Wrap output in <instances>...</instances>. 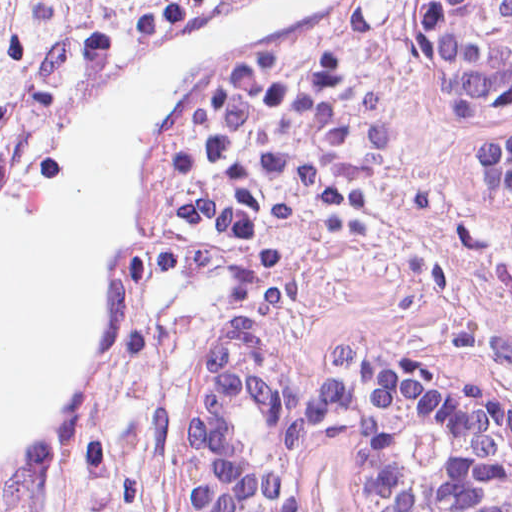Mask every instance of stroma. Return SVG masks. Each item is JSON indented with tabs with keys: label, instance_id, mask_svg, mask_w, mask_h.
Returning <instances> with one entry per match:
<instances>
[{
	"label": "stroma",
	"instance_id": "stroma-1",
	"mask_svg": "<svg viewBox=\"0 0 512 512\" xmlns=\"http://www.w3.org/2000/svg\"><path fill=\"white\" fill-rule=\"evenodd\" d=\"M300 36L365 80L391 129V156L380 181L340 211L283 279L282 309L298 349L317 355L426 338L512 387V196L477 187L471 131L415 119L405 5L353 0ZM88 418L100 430L97 397ZM85 463L90 474L116 479L96 443ZM317 512H350V484L349 501L326 497Z\"/></svg>",
	"mask_w": 512,
	"mask_h": 512
}]
</instances>
